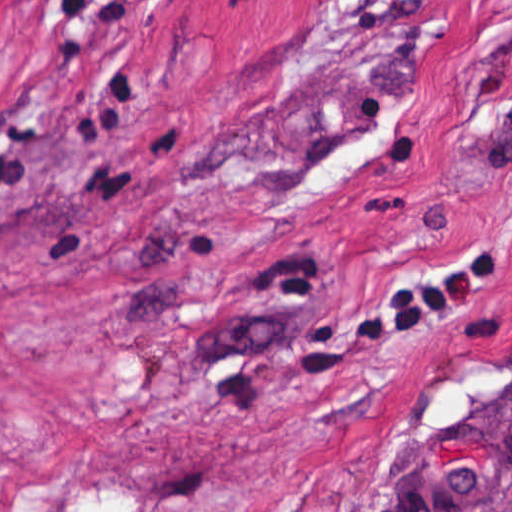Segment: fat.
Segmentation results:
<instances>
[{
	"label": "fat",
	"instance_id": "53f6f03d",
	"mask_svg": "<svg viewBox=\"0 0 512 512\" xmlns=\"http://www.w3.org/2000/svg\"><path fill=\"white\" fill-rule=\"evenodd\" d=\"M117 494L105 495L91 499L82 507L84 512H130V505L115 498Z\"/></svg>",
	"mask_w": 512,
	"mask_h": 512
}]
</instances>
